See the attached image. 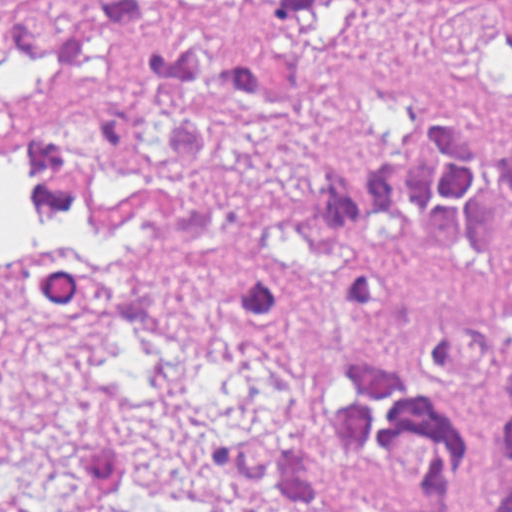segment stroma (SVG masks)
Instances as JSON below:
<instances>
[{
  "instance_id": "stroma-1",
  "label": "stroma",
  "mask_w": 512,
  "mask_h": 512,
  "mask_svg": "<svg viewBox=\"0 0 512 512\" xmlns=\"http://www.w3.org/2000/svg\"><path fill=\"white\" fill-rule=\"evenodd\" d=\"M255 67L284 109L226 160L217 197L263 215L319 167L356 162L398 126L439 118L512 138V0H360L311 23L263 21ZM9 86L0 58V112ZM512 264V241L496 248ZM350 335L342 268H324L286 309L251 324H80L47 313L0 225V512H53L74 440L145 447L171 461L202 512H265L211 469L213 436L276 419L291 373ZM483 413L477 512L501 481Z\"/></svg>"
}]
</instances>
